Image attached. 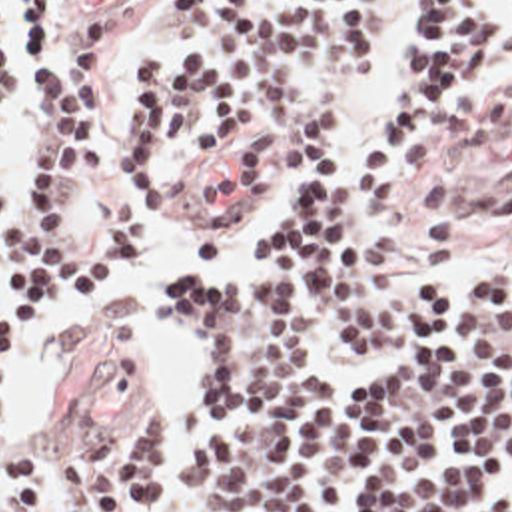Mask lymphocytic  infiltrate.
I'll list each match as a JSON object with an SVG mask.
<instances>
[{
	"instance_id": "obj_1",
	"label": "lymphocytic infiltrate",
	"mask_w": 512,
	"mask_h": 512,
	"mask_svg": "<svg viewBox=\"0 0 512 512\" xmlns=\"http://www.w3.org/2000/svg\"><path fill=\"white\" fill-rule=\"evenodd\" d=\"M388 3L165 0L163 27L189 55L131 67L113 215L87 231L83 191L101 193L117 167L113 25L67 23L63 67L49 51L57 0H19L35 137L11 201L0 189V385L17 329H41L57 299L95 301L131 265L141 217L207 159L269 199L261 263L163 283L199 359L193 432L171 476L169 423L149 411L59 458L11 452L23 512H47L63 486L83 512H163L169 486L201 512H512V265L482 285L406 283L386 273L392 241L371 237L428 123L512 73V0H414L363 149L331 167ZM15 9L0 0V133Z\"/></svg>"
}]
</instances>
